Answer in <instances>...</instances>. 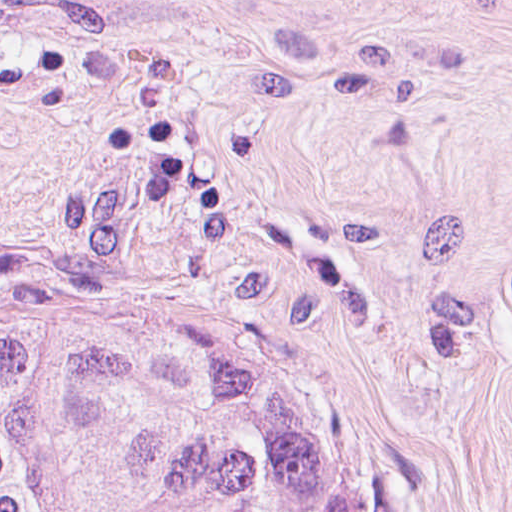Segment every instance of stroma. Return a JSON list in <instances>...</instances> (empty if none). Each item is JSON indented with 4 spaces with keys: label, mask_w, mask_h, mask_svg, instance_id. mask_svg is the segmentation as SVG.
<instances>
[{
    "label": "stroma",
    "mask_w": 512,
    "mask_h": 512,
    "mask_svg": "<svg viewBox=\"0 0 512 512\" xmlns=\"http://www.w3.org/2000/svg\"><path fill=\"white\" fill-rule=\"evenodd\" d=\"M118 293L313 331L406 512H512V0H0V326Z\"/></svg>",
    "instance_id": "obj_1"
}]
</instances>
